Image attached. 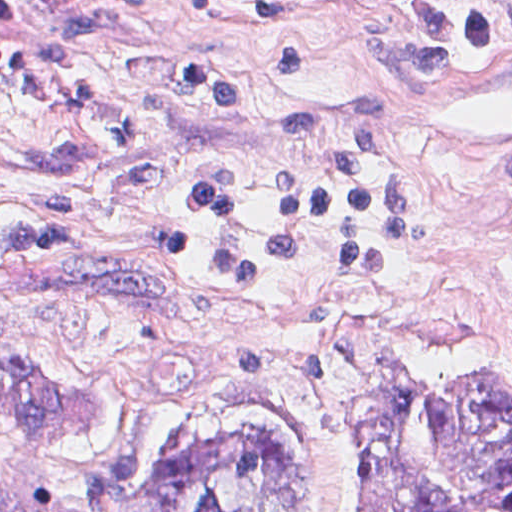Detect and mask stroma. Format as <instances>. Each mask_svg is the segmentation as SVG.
<instances>
[{
  "label": "stroma",
  "mask_w": 512,
  "mask_h": 512,
  "mask_svg": "<svg viewBox=\"0 0 512 512\" xmlns=\"http://www.w3.org/2000/svg\"><path fill=\"white\" fill-rule=\"evenodd\" d=\"M373 1L512 0H0V512L1 316L46 369L89 389L77 437L155 450L219 406H272L307 430L325 482L350 493L355 396L376 359L454 371L512 358V51L479 54ZM77 14L111 32L95 93L30 112L23 129L54 136L102 116L135 119L160 161L149 182L126 177L128 147L70 175L1 176V43L50 41ZM193 46H227L251 108L202 102L158 57ZM255 46H302L314 70L274 72ZM348 86L385 107L409 195L400 272L310 304H254L118 256L179 224L184 267H202L212 229L180 187L205 175L244 185L233 235H262L286 166L338 154L330 137L279 140L275 120ZM50 195L92 204L68 253L83 263L1 264V221Z\"/></svg>",
  "instance_id": "35a3bbf8"
}]
</instances>
